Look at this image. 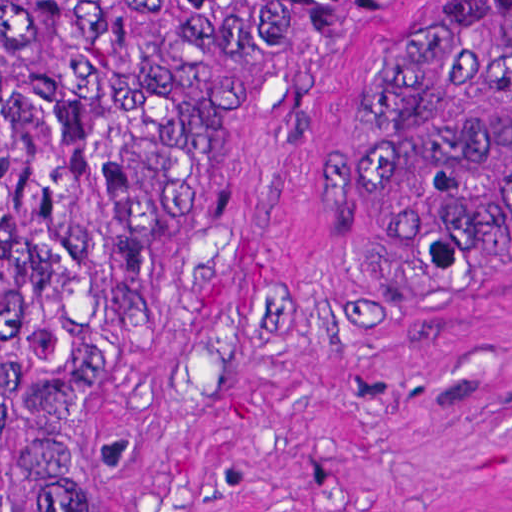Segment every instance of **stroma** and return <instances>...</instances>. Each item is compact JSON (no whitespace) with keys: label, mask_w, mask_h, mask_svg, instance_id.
Returning <instances> with one entry per match:
<instances>
[{"label":"stroma","mask_w":512,"mask_h":512,"mask_svg":"<svg viewBox=\"0 0 512 512\" xmlns=\"http://www.w3.org/2000/svg\"><path fill=\"white\" fill-rule=\"evenodd\" d=\"M396 3L253 1L145 253L77 512H417L512 488V241L397 318H344L330 282V187Z\"/></svg>","instance_id":"35a3bbf8"}]
</instances>
